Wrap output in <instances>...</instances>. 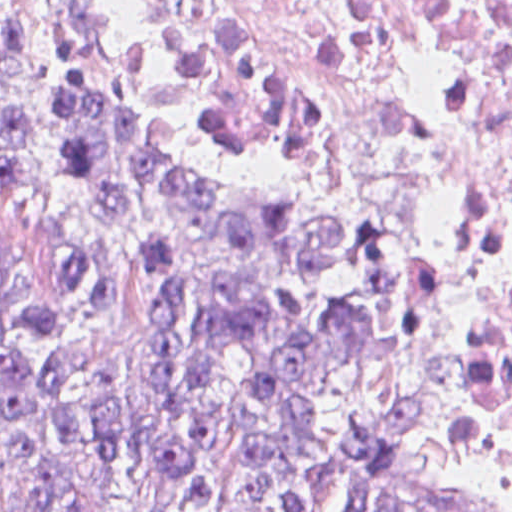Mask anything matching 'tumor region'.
<instances>
[{
	"label": "tumor region",
	"mask_w": 512,
	"mask_h": 512,
	"mask_svg": "<svg viewBox=\"0 0 512 512\" xmlns=\"http://www.w3.org/2000/svg\"><path fill=\"white\" fill-rule=\"evenodd\" d=\"M437 294L179 164L69 0H0V512H495Z\"/></svg>",
	"instance_id": "tumor-region-1"
}]
</instances>
